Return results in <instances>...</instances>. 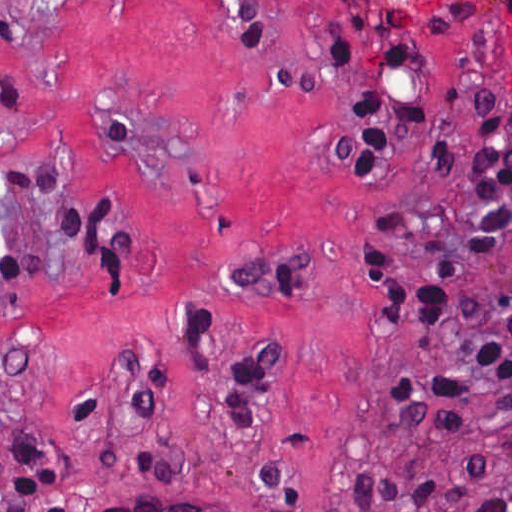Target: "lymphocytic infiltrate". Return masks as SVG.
Wrapping results in <instances>:
<instances>
[{
  "instance_id": "obj_1",
  "label": "lymphocytic infiltrate",
  "mask_w": 512,
  "mask_h": 512,
  "mask_svg": "<svg viewBox=\"0 0 512 512\" xmlns=\"http://www.w3.org/2000/svg\"><path fill=\"white\" fill-rule=\"evenodd\" d=\"M334 62L358 69L355 46L327 37ZM421 57L403 46H391L382 67L411 71ZM346 92L353 98L360 121L354 135L339 137L338 155L362 173H381L391 164L396 146L409 130L425 126L450 95H407L363 82ZM474 142L467 158L466 203L473 220L465 250L485 259L512 231V148L492 123L471 104ZM433 156L444 176L452 169V148L446 138L433 140ZM72 183L61 161L47 153L13 168L0 170V184L20 194H49ZM92 205L79 197L62 204L55 216L84 253L79 231ZM410 217L406 210L387 213L377 233L354 230L355 259L364 291L377 287L384 293L386 318L405 329H432L439 322L449 293L458 280V268L447 257H437L427 276L410 282L394 268L389 240L404 232ZM137 250V232L131 222L114 212V225L104 240V266L108 286L117 281ZM6 279L23 272L15 256H0ZM218 291L253 299H304L310 291V274L271 260H244ZM457 318L470 332V343L445 362L403 367L389 375L384 394L388 436L393 446L415 441L423 424L441 434L461 436L470 430L463 408L475 398L495 402L512 428V287L492 298L462 300ZM193 342L208 339L211 321L196 302L190 314ZM288 346L285 339L258 341L231 376L226 400L234 425L241 431H258L263 389L278 358ZM131 408L150 418L161 401V362L140 351L118 374ZM73 413L87 422L98 416L99 404L84 389L75 399ZM130 476L144 481H180V466L155 457H136L126 463ZM457 481L433 477L402 476L363 459L350 477L347 497L362 512H512V484L488 485L489 473L480 456L466 455L456 465ZM255 474L265 490L286 508L305 509L302 480L272 461L256 463ZM8 498L13 512H29L32 504L57 490L54 463L25 440L13 427L6 451ZM45 512H69L59 505ZM96 512H216V508L187 502L177 505L150 498H127L106 504Z\"/></svg>"
}]
</instances>
